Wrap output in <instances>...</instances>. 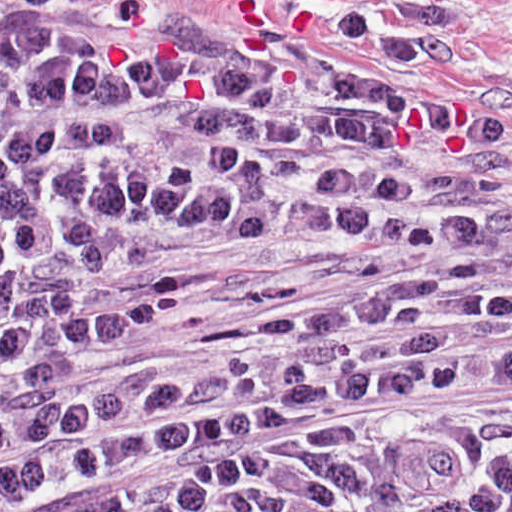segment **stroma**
Segmentation results:
<instances>
[{
  "instance_id": "obj_1",
  "label": "stroma",
  "mask_w": 512,
  "mask_h": 512,
  "mask_svg": "<svg viewBox=\"0 0 512 512\" xmlns=\"http://www.w3.org/2000/svg\"><path fill=\"white\" fill-rule=\"evenodd\" d=\"M0 9L117 21L160 49L287 58L300 71L365 74L421 95L451 118L466 198L512 222V0H0ZM414 263L409 239L153 231L88 263L82 282L103 288L200 266L205 288L193 305L91 346L75 382L104 387L288 301L360 290Z\"/></svg>"
}]
</instances>
